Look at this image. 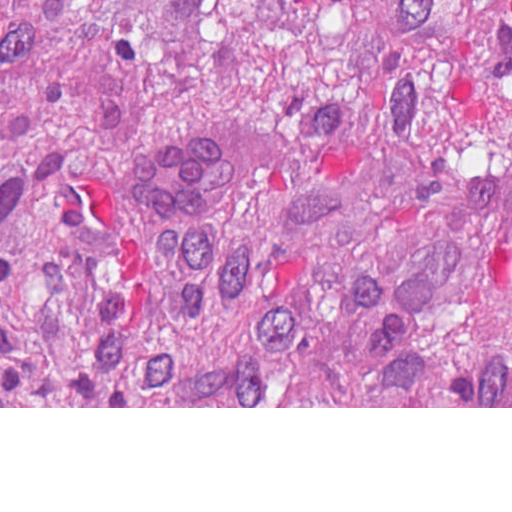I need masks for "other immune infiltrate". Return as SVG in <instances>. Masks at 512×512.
Here are the masks:
<instances>
[{
  "mask_svg": "<svg viewBox=\"0 0 512 512\" xmlns=\"http://www.w3.org/2000/svg\"><path fill=\"white\" fill-rule=\"evenodd\" d=\"M230 183L229 123L184 125L137 158L134 206L154 227H185L212 211Z\"/></svg>",
  "mask_w": 512,
  "mask_h": 512,
  "instance_id": "bc1004c8",
  "label": "other immune infiltrate"
}]
</instances>
